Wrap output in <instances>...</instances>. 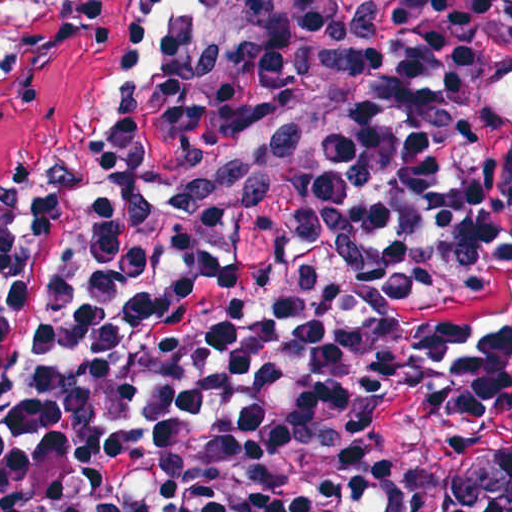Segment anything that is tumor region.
Instances as JSON below:
<instances>
[{
    "label": "tumor region",
    "instance_id": "obj_1",
    "mask_svg": "<svg viewBox=\"0 0 512 512\" xmlns=\"http://www.w3.org/2000/svg\"><path fill=\"white\" fill-rule=\"evenodd\" d=\"M113 16L114 0H0V57L69 55ZM449 512H512V454L484 461Z\"/></svg>",
    "mask_w": 512,
    "mask_h": 512
}]
</instances>
